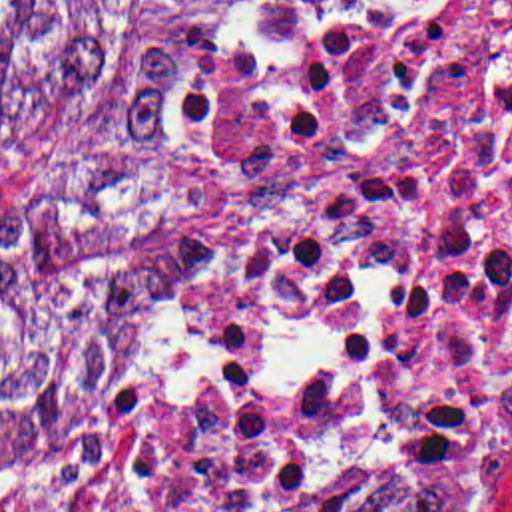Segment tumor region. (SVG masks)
<instances>
[{
  "mask_svg": "<svg viewBox=\"0 0 512 512\" xmlns=\"http://www.w3.org/2000/svg\"><path fill=\"white\" fill-rule=\"evenodd\" d=\"M267 0H0V474L183 378L229 290ZM321 512H460L378 482Z\"/></svg>",
  "mask_w": 512,
  "mask_h": 512,
  "instance_id": "tumor-region-1",
  "label": "tumor region"
}]
</instances>
